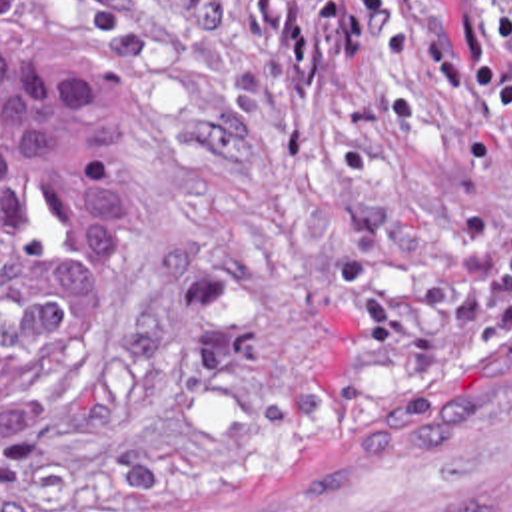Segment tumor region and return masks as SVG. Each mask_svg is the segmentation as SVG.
Masks as SVG:
<instances>
[{
	"label": "tumor region",
	"instance_id": "obj_1",
	"mask_svg": "<svg viewBox=\"0 0 512 512\" xmlns=\"http://www.w3.org/2000/svg\"><path fill=\"white\" fill-rule=\"evenodd\" d=\"M134 260L132 110L70 0H0V424L84 374Z\"/></svg>",
	"mask_w": 512,
	"mask_h": 512
}]
</instances>
